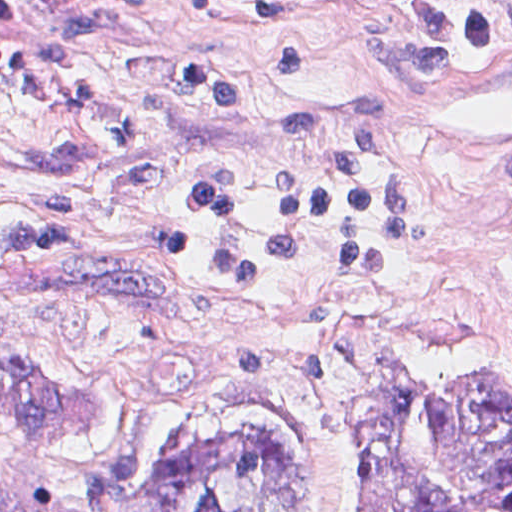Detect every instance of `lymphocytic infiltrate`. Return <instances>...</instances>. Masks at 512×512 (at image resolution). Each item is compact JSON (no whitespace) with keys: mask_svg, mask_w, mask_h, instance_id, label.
I'll use <instances>...</instances> for the list:
<instances>
[{"mask_svg":"<svg viewBox=\"0 0 512 512\" xmlns=\"http://www.w3.org/2000/svg\"><path fill=\"white\" fill-rule=\"evenodd\" d=\"M434 27L479 54L512 51V1H373ZM111 32L76 15L50 41L1 43V176H64L128 147L126 177L149 182L160 161L143 128L127 116H102L54 136L23 129L30 112L87 103L97 61ZM227 46L157 50L183 87L216 109H249L252 95L232 74ZM277 73H305L302 46H255ZM279 140L330 137L338 154L280 176L271 227L255 238L233 235L244 185L221 175L181 184L185 205L211 226L202 267H184L187 226L173 224L118 256L166 264L199 285L254 304H310L401 271L409 250V195L385 133L379 93L358 86L291 110L275 120ZM92 204L79 197L37 199L17 220L1 221V264H81L68 256L86 231Z\"/></svg>","mask_w":512,"mask_h":512,"instance_id":"f902f5d3","label":"lymphocytic infiltrate"}]
</instances>
